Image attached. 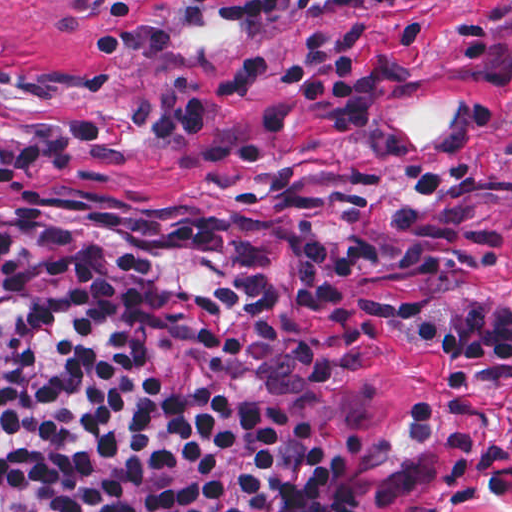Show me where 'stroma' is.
Wrapping results in <instances>:
<instances>
[{"mask_svg": "<svg viewBox=\"0 0 512 512\" xmlns=\"http://www.w3.org/2000/svg\"><path fill=\"white\" fill-rule=\"evenodd\" d=\"M221 0H0V144L22 127L120 109L194 65L228 69L249 51L298 57L312 29L369 23L367 69L383 82L368 132L331 136L306 110L266 131L261 112L294 89L261 82L244 99L201 97L206 127L272 153L207 163L200 143L103 130L120 156L77 150L0 197L101 194L212 215H268L311 248L348 259L372 306L512 308V0H421L337 9L270 29L221 25ZM355 384L330 438L368 432L367 512H512V432L433 446L422 425L441 359L360 326L343 337Z\"/></svg>", "mask_w": 512, "mask_h": 512, "instance_id": "1", "label": "stroma"}]
</instances>
